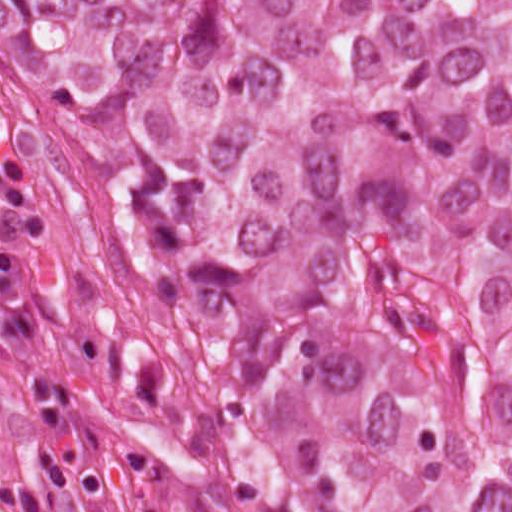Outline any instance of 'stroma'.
Listing matches in <instances>:
<instances>
[{"mask_svg":"<svg viewBox=\"0 0 512 512\" xmlns=\"http://www.w3.org/2000/svg\"><path fill=\"white\" fill-rule=\"evenodd\" d=\"M50 375L72 387L56 444L70 462L98 472L102 491L80 495L63 486L48 488L43 512H170L94 386L39 318L31 334L0 335V484L20 483L30 471L35 457L30 382Z\"/></svg>","mask_w":512,"mask_h":512,"instance_id":"1","label":"stroma"}]
</instances>
